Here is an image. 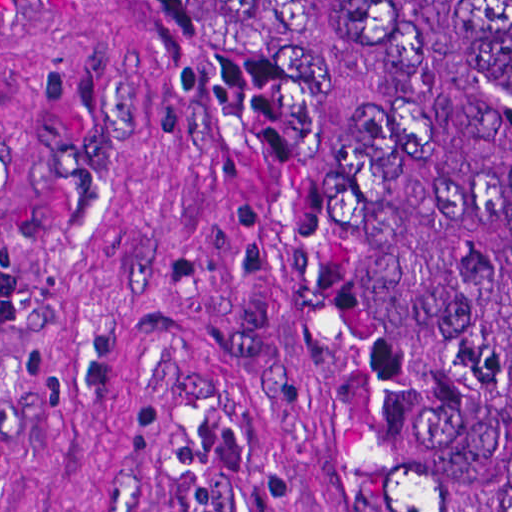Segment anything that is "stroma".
<instances>
[{
    "mask_svg": "<svg viewBox=\"0 0 512 512\" xmlns=\"http://www.w3.org/2000/svg\"><path fill=\"white\" fill-rule=\"evenodd\" d=\"M0 512H402L322 364L267 177L161 47L0 21Z\"/></svg>",
    "mask_w": 512,
    "mask_h": 512,
    "instance_id": "1",
    "label": "stroma"
}]
</instances>
